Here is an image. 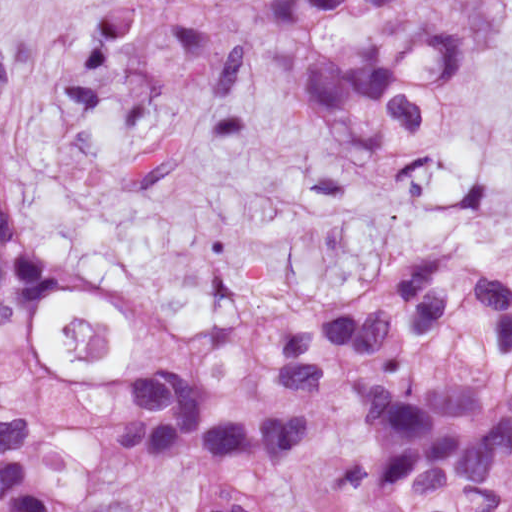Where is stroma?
<instances>
[{
	"instance_id": "stroma-1",
	"label": "stroma",
	"mask_w": 512,
	"mask_h": 512,
	"mask_svg": "<svg viewBox=\"0 0 512 512\" xmlns=\"http://www.w3.org/2000/svg\"><path fill=\"white\" fill-rule=\"evenodd\" d=\"M263 0H0L2 205L77 283L40 327L98 392L148 324L228 331L369 288L450 246L512 269V0H355L331 50L378 67L411 22L454 55L396 154L341 137L262 30ZM68 317L106 318L101 363ZM117 469L56 512H131Z\"/></svg>"
}]
</instances>
